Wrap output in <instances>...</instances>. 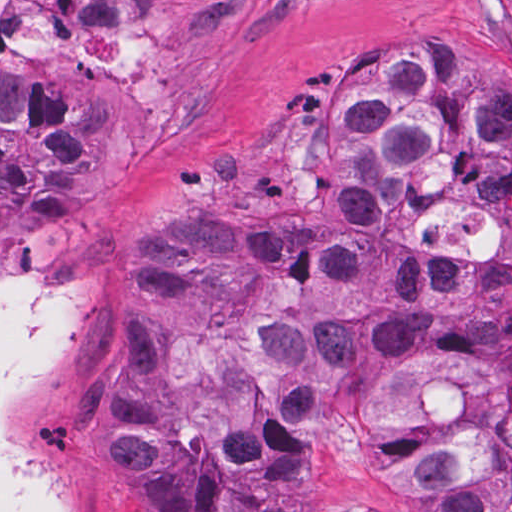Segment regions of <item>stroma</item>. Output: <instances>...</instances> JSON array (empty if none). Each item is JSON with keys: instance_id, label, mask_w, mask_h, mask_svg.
Masks as SVG:
<instances>
[{"instance_id": "obj_1", "label": "stroma", "mask_w": 512, "mask_h": 512, "mask_svg": "<svg viewBox=\"0 0 512 512\" xmlns=\"http://www.w3.org/2000/svg\"><path fill=\"white\" fill-rule=\"evenodd\" d=\"M38 53L0 51V73L53 83L84 111L61 209L0 243V282L66 276L88 315L43 384L29 445L63 512H118L92 464L82 410L139 235L218 187L240 155L292 124L335 73L415 37L471 38L486 94L512 111V0H35ZM512 206L496 275L512 325Z\"/></svg>"}]
</instances>
